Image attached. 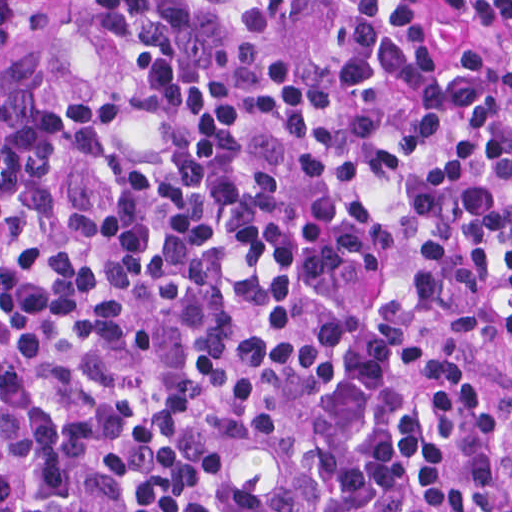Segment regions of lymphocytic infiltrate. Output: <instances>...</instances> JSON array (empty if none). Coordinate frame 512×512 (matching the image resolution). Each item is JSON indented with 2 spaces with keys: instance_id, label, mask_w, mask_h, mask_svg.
Wrapping results in <instances>:
<instances>
[{
  "instance_id": "1",
  "label": "lymphocytic infiltrate",
  "mask_w": 512,
  "mask_h": 512,
  "mask_svg": "<svg viewBox=\"0 0 512 512\" xmlns=\"http://www.w3.org/2000/svg\"><path fill=\"white\" fill-rule=\"evenodd\" d=\"M512 0H1V512H512Z\"/></svg>"
}]
</instances>
